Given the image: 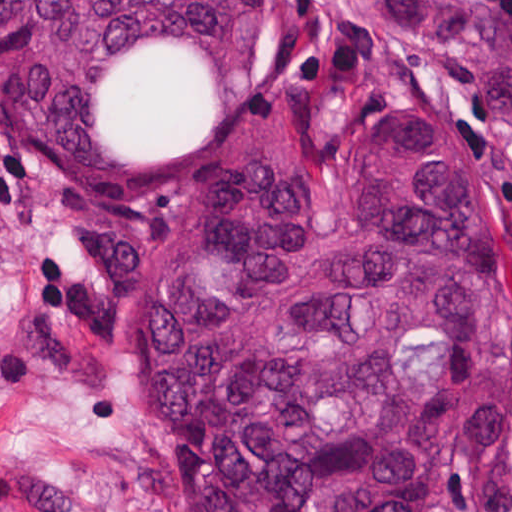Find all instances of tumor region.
Returning <instances> with one entry per match:
<instances>
[{"label":"tumor region","instance_id":"e687c5a6","mask_svg":"<svg viewBox=\"0 0 512 512\" xmlns=\"http://www.w3.org/2000/svg\"><path fill=\"white\" fill-rule=\"evenodd\" d=\"M386 5L512 124L505 8ZM276 32L277 0H0L20 130L82 193L204 158ZM372 118L221 187L134 297L136 383L186 512H424L445 456L512 441L511 265L465 133L432 103Z\"/></svg>","mask_w":512,"mask_h":512}]
</instances>
